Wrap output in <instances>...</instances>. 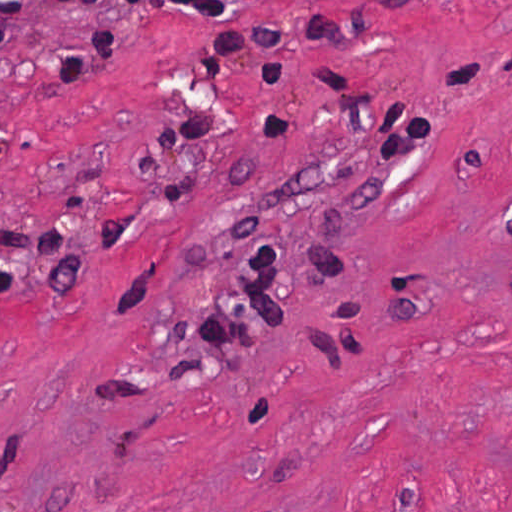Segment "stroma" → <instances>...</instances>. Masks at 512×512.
Returning <instances> with one entry per match:
<instances>
[{"instance_id": "35a3bbf8", "label": "stroma", "mask_w": 512, "mask_h": 512, "mask_svg": "<svg viewBox=\"0 0 512 512\" xmlns=\"http://www.w3.org/2000/svg\"><path fill=\"white\" fill-rule=\"evenodd\" d=\"M231 1L22 0L0 512H512V0Z\"/></svg>"}]
</instances>
